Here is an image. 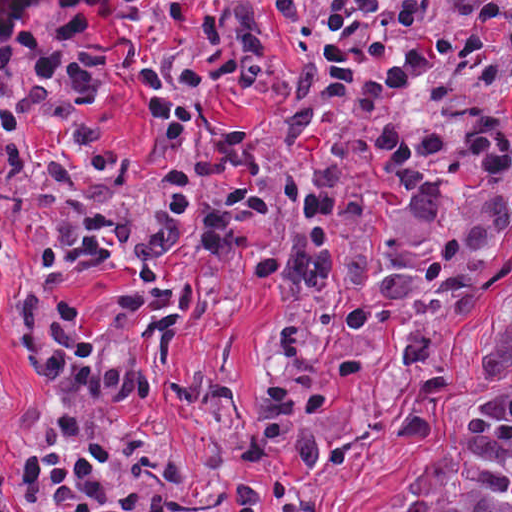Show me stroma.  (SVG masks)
Segmentation results:
<instances>
[{
	"label": "stroma",
	"instance_id": "stroma-1",
	"mask_svg": "<svg viewBox=\"0 0 512 512\" xmlns=\"http://www.w3.org/2000/svg\"><path fill=\"white\" fill-rule=\"evenodd\" d=\"M511 303L512 260L435 294V339L451 376L452 421L480 394L486 380L480 348ZM264 374L150 420L173 440L193 477L204 475L209 453L240 434ZM446 430L418 441L395 379L375 389L333 454L313 512H393L416 466Z\"/></svg>",
	"mask_w": 512,
	"mask_h": 512
}]
</instances>
